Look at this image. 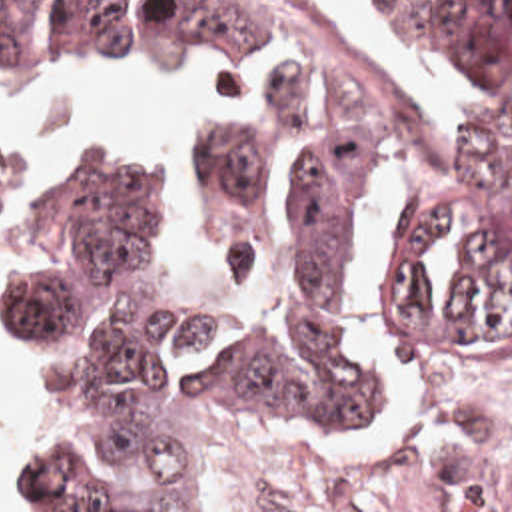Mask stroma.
Here are the masks:
<instances>
[{"label": "stroma", "mask_w": 512, "mask_h": 512, "mask_svg": "<svg viewBox=\"0 0 512 512\" xmlns=\"http://www.w3.org/2000/svg\"><path fill=\"white\" fill-rule=\"evenodd\" d=\"M85 77L63 73V71H23L7 61L0 59V83L7 89L39 95V97H95L91 91L81 87L79 83ZM134 123L119 125L103 135L89 139L79 145H53L45 149H35L21 153L19 159L9 169V175L17 187L13 213L5 221L7 213V173H0V225L5 221V229L0 241V319L3 301H5V253L7 241L13 225L21 217L23 209L31 203V199L41 191V187L57 173V169L81 151L89 143H125L132 139ZM364 325L368 346L384 374L390 404L378 424V428L350 420L332 408L298 398V396H224L216 408L206 416L210 448L214 456V464L218 466H238L248 468L252 474V430L274 422L282 416H320L332 424H338L346 430H388L402 408L410 398L446 392L450 396L462 398L472 404L494 402L512 398V390L504 392H460L404 362L398 360L392 340L388 336L382 289L378 277V265H374L366 285H364ZM15 452L21 456L25 466V434H7ZM0 434V450H1Z\"/></svg>", "instance_id": "stroma-1"}]
</instances>
